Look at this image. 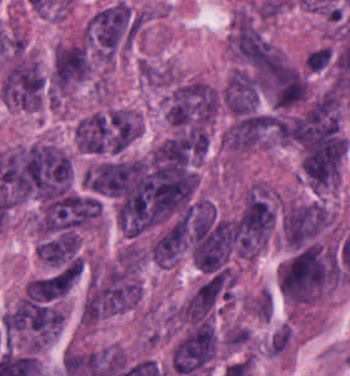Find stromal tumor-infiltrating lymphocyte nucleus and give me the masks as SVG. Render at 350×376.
I'll return each instance as SVG.
<instances>
[{
    "mask_svg": "<svg viewBox=\"0 0 350 376\" xmlns=\"http://www.w3.org/2000/svg\"><path fill=\"white\" fill-rule=\"evenodd\" d=\"M306 68H307V70H309V71H311V72H319V71L314 70V69H312V68H309V67H307V66H306Z\"/></svg>",
    "mask_w": 350,
    "mask_h": 376,
    "instance_id": "bc302bb0",
    "label": "stromal tumor-infiltrating lymphocyte nucleus"
}]
</instances>
